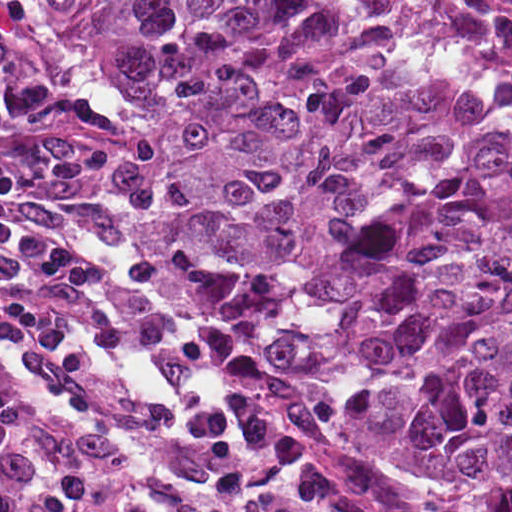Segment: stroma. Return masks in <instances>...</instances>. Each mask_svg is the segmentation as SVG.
Instances as JSON below:
<instances>
[{"label": "stroma", "mask_w": 512, "mask_h": 512, "mask_svg": "<svg viewBox=\"0 0 512 512\" xmlns=\"http://www.w3.org/2000/svg\"><path fill=\"white\" fill-rule=\"evenodd\" d=\"M31 1H343L355 17L389 46L421 65L464 85L486 100L512 111V97L495 94L466 82L404 45L368 10L365 1H512V0H0V27L21 38L45 55L67 65L92 89L131 116L142 131L149 129L129 96L101 69L86 44L71 30L45 14ZM150 134V133H149ZM160 173L161 165H160ZM172 196L162 176V199L149 220L137 251V269L149 303L174 330L215 352L238 355L254 361L262 396L286 433L311 459L342 475L375 499L430 512H486L485 508L449 483L430 478H411L377 469L356 458L344 445L315 433L303 422L287 398L271 362L272 342L258 337H240L190 324L180 313L169 288L172 237L169 224Z\"/></svg>", "instance_id": "stroma-1"}]
</instances>
